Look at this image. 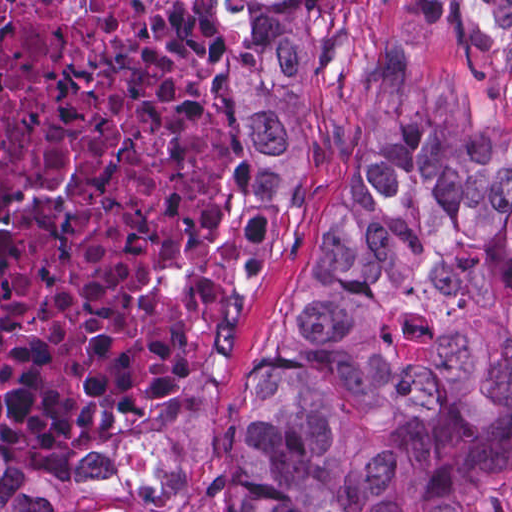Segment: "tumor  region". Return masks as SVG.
I'll list each match as a JSON object with an SVG mask.
<instances>
[{"label":"tumor region","instance_id":"obj_1","mask_svg":"<svg viewBox=\"0 0 512 512\" xmlns=\"http://www.w3.org/2000/svg\"><path fill=\"white\" fill-rule=\"evenodd\" d=\"M250 174H302L339 90L328 0H206ZM512 468V143L449 81L393 91L275 317L210 512H493ZM0 512H100L0 443Z\"/></svg>","mask_w":512,"mask_h":512}]
</instances>
